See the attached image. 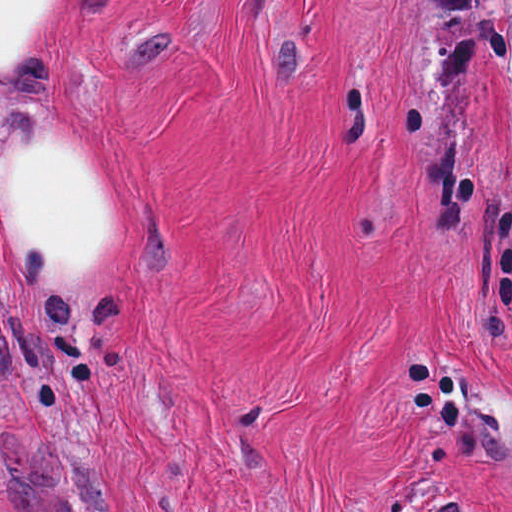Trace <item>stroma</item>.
<instances>
[{"label":"stroma","instance_id":"stroma-1","mask_svg":"<svg viewBox=\"0 0 512 512\" xmlns=\"http://www.w3.org/2000/svg\"><path fill=\"white\" fill-rule=\"evenodd\" d=\"M30 121L121 254L0 280V512H512V0H74Z\"/></svg>","mask_w":512,"mask_h":512}]
</instances>
